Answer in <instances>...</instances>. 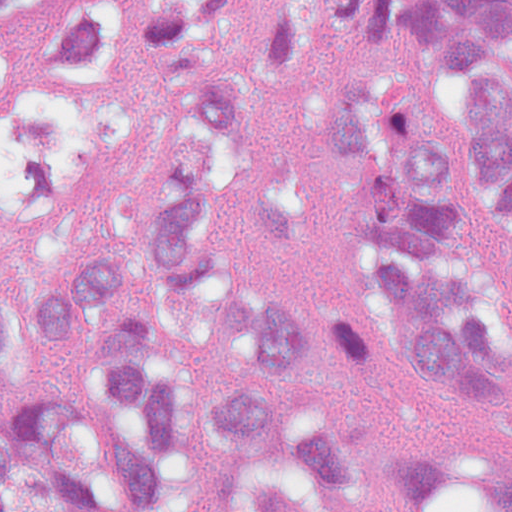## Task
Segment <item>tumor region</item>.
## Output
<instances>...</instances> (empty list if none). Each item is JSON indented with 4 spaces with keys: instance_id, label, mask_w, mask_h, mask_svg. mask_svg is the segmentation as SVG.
<instances>
[{
    "instance_id": "obj_1",
    "label": "tumor region",
    "mask_w": 512,
    "mask_h": 512,
    "mask_svg": "<svg viewBox=\"0 0 512 512\" xmlns=\"http://www.w3.org/2000/svg\"><path fill=\"white\" fill-rule=\"evenodd\" d=\"M0 0V426L50 457L87 512H196L239 457L275 460L335 508L512 512V335L459 185V147L419 89L334 77L317 100L351 206L348 314L240 279L237 229L309 242L296 174L259 106L312 57L289 6ZM419 21L460 71L488 201L512 205V0H331L354 38ZM512 281V234L504 248ZM381 347L427 397L500 426L481 447L361 448L265 396L372 383ZM0 512H78L54 465L0 437Z\"/></svg>"
}]
</instances>
